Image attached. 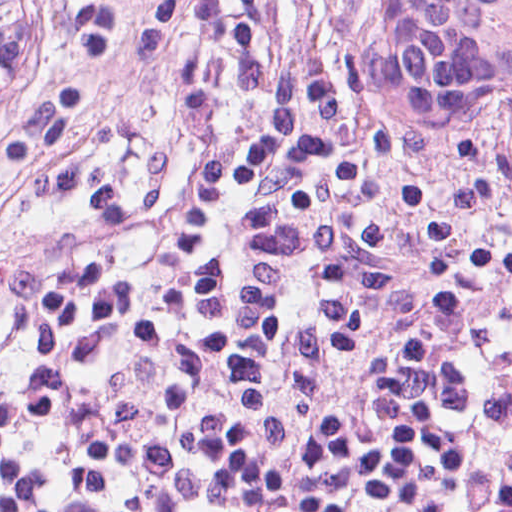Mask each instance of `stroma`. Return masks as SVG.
Here are the masks:
<instances>
[{"instance_id":"stroma-1","label":"stroma","mask_w":512,"mask_h":512,"mask_svg":"<svg viewBox=\"0 0 512 512\" xmlns=\"http://www.w3.org/2000/svg\"><path fill=\"white\" fill-rule=\"evenodd\" d=\"M43 1V0H42ZM255 114V54L248 75V100L241 112L230 144L247 136ZM85 224L95 223H41L35 222L17 247L0 242V303L14 278L29 257L50 242Z\"/></svg>"}]
</instances>
